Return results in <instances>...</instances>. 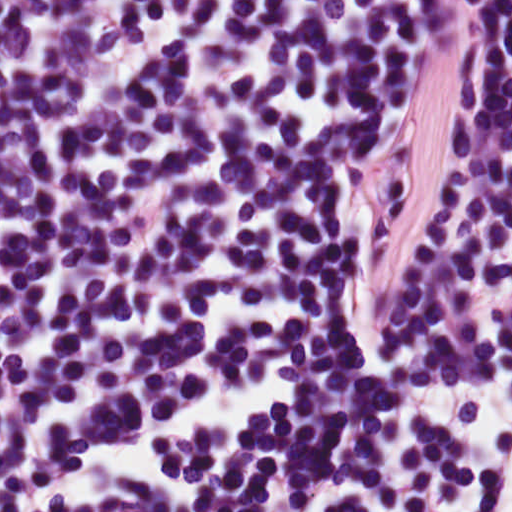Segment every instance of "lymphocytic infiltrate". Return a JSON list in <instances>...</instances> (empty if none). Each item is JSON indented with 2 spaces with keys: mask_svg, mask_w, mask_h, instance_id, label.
<instances>
[{
  "mask_svg": "<svg viewBox=\"0 0 512 512\" xmlns=\"http://www.w3.org/2000/svg\"><path fill=\"white\" fill-rule=\"evenodd\" d=\"M0 512H512V0H0Z\"/></svg>",
  "mask_w": 512,
  "mask_h": 512,
  "instance_id": "lymphocytic-infiltrate-1",
  "label": "lymphocytic infiltrate"
}]
</instances>
